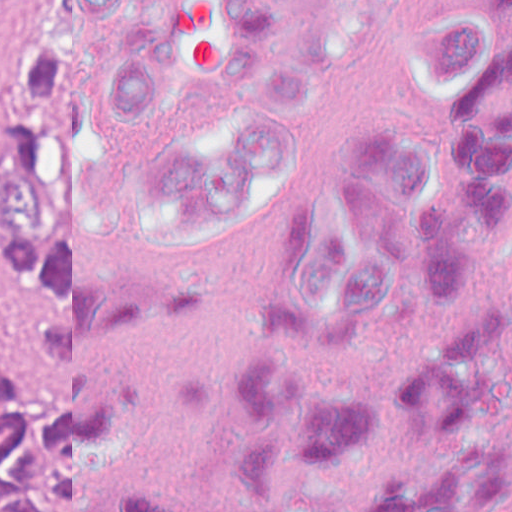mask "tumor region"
Segmentation results:
<instances>
[{"label":"tumor region","mask_w":512,"mask_h":512,"mask_svg":"<svg viewBox=\"0 0 512 512\" xmlns=\"http://www.w3.org/2000/svg\"><path fill=\"white\" fill-rule=\"evenodd\" d=\"M0 255L33 301L30 150L17 87L0 167ZM0 512H42V464L33 426V335L28 344L0 355Z\"/></svg>","instance_id":"obj_1"}]
</instances>
